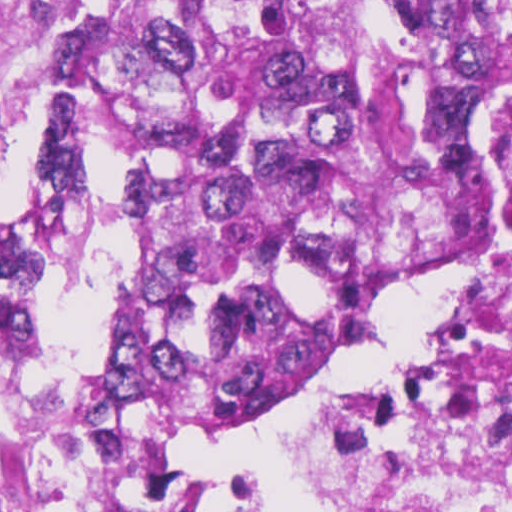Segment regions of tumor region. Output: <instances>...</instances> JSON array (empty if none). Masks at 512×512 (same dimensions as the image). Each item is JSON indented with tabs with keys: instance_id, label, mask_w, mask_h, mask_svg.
<instances>
[{
	"instance_id": "1",
	"label": "tumor region",
	"mask_w": 512,
	"mask_h": 512,
	"mask_svg": "<svg viewBox=\"0 0 512 512\" xmlns=\"http://www.w3.org/2000/svg\"><path fill=\"white\" fill-rule=\"evenodd\" d=\"M49 1L67 100L3 274L64 289L124 246L59 379L49 311L0 299V512H187L441 137L453 0Z\"/></svg>"
}]
</instances>
